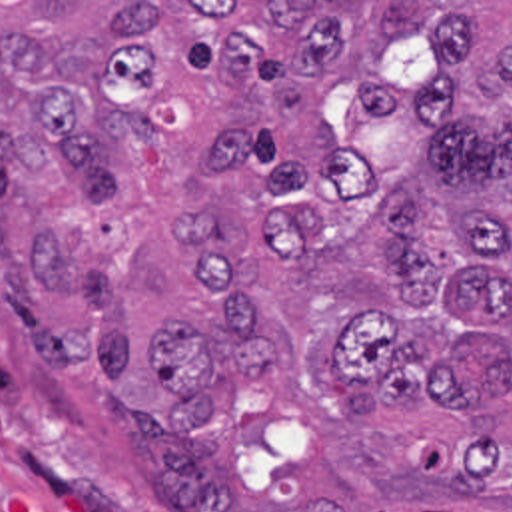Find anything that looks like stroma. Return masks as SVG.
Here are the masks:
<instances>
[{
    "label": "stroma",
    "instance_id": "obj_1",
    "mask_svg": "<svg viewBox=\"0 0 512 512\" xmlns=\"http://www.w3.org/2000/svg\"><path fill=\"white\" fill-rule=\"evenodd\" d=\"M97 367L38 361L0 304V512H165L125 429L93 411Z\"/></svg>",
    "mask_w": 512,
    "mask_h": 512
}]
</instances>
